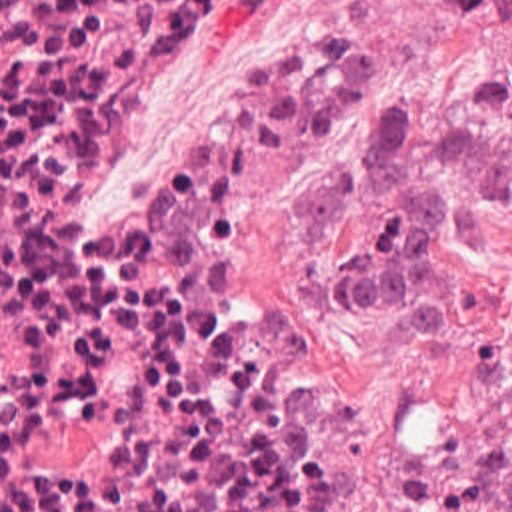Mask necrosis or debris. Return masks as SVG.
Returning <instances> with one entry per match:
<instances>
[{"label": "necrosis or debris", "mask_w": 512, "mask_h": 512, "mask_svg": "<svg viewBox=\"0 0 512 512\" xmlns=\"http://www.w3.org/2000/svg\"><path fill=\"white\" fill-rule=\"evenodd\" d=\"M198 0H0V512H470L486 435L372 471L220 301L244 189L350 94L334 28L220 42L102 215L86 153L194 60Z\"/></svg>", "instance_id": "4bbe7bcc"}]
</instances>
